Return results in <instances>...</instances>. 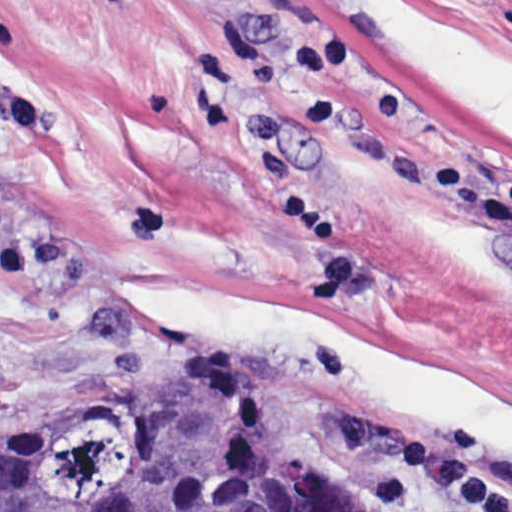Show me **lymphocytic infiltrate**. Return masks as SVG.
<instances>
[{"mask_svg": "<svg viewBox=\"0 0 512 512\" xmlns=\"http://www.w3.org/2000/svg\"><path fill=\"white\" fill-rule=\"evenodd\" d=\"M414 483L440 487L460 512H512V488L487 463L486 439L458 432L447 443L411 436L394 448L381 504L400 502Z\"/></svg>", "mask_w": 512, "mask_h": 512, "instance_id": "lymphocytic-infiltrate-1", "label": "lymphocytic infiltrate"}]
</instances>
